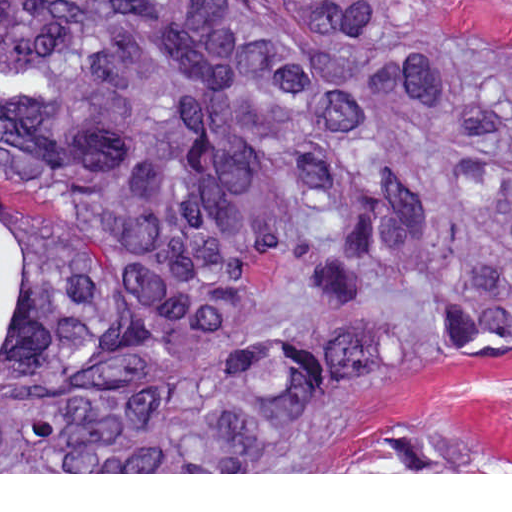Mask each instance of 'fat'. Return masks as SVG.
I'll return each instance as SVG.
<instances>
[{"label": "fat", "mask_w": 512, "mask_h": 512, "mask_svg": "<svg viewBox=\"0 0 512 512\" xmlns=\"http://www.w3.org/2000/svg\"><path fill=\"white\" fill-rule=\"evenodd\" d=\"M24 275V240L17 233L0 227V357L8 322Z\"/></svg>", "instance_id": "obj_1"}]
</instances>
